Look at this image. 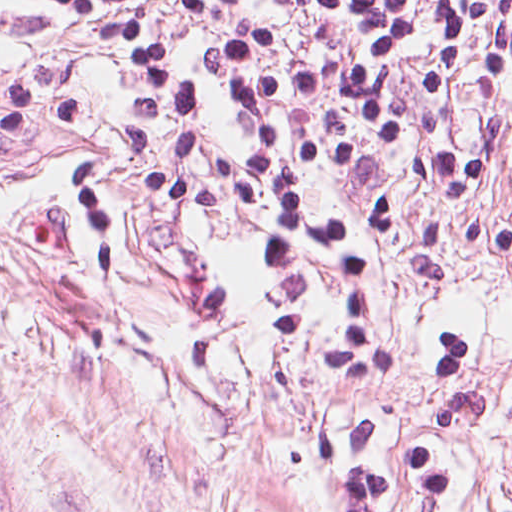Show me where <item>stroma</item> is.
I'll use <instances>...</instances> for the list:
<instances>
[{"label": "stroma", "instance_id": "1", "mask_svg": "<svg viewBox=\"0 0 512 512\" xmlns=\"http://www.w3.org/2000/svg\"><path fill=\"white\" fill-rule=\"evenodd\" d=\"M163 39L210 106L212 259L242 341L179 354L185 253L123 154L117 52L38 0H0V83L60 75L79 120L0 133V476L30 512H512V253L458 252L447 284L414 265L421 214L395 224L373 285L393 355L345 362L339 312L314 272L261 274L242 205L244 118L201 71L213 23L154 0ZM469 143L500 124L472 201L512 219V79L464 94ZM79 168L114 225V293L82 270ZM408 158L316 177L323 207L364 204Z\"/></svg>", "mask_w": 512, "mask_h": 512}]
</instances>
